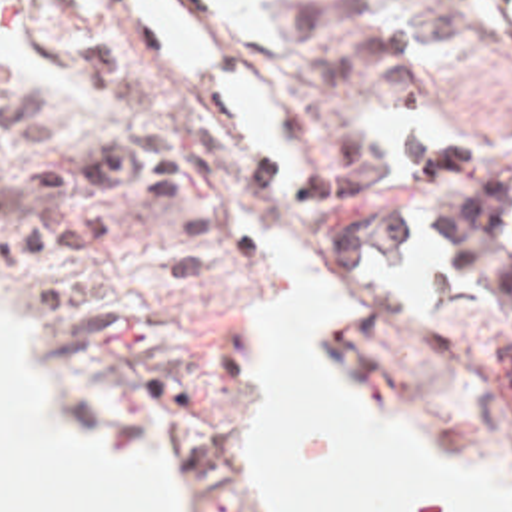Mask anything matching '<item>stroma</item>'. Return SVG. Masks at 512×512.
<instances>
[{
    "instance_id": "stroma-1",
    "label": "stroma",
    "mask_w": 512,
    "mask_h": 512,
    "mask_svg": "<svg viewBox=\"0 0 512 512\" xmlns=\"http://www.w3.org/2000/svg\"><path fill=\"white\" fill-rule=\"evenodd\" d=\"M169 2L211 38L217 66L275 70L339 176V214L303 216L223 136L211 78L181 82L131 0H107L105 20L76 0H0V62L58 108L50 146L0 156L40 168L111 134L115 110L76 72V48L100 42L209 210L201 285L157 273L151 222L107 186L52 202L109 214L94 244L26 254L0 228V267L44 313L74 393L167 441L197 479V512H235L225 425L255 391L263 273L247 234L289 230L385 297L329 373L379 389L421 449L491 465L512 489V40L493 0H255L279 56L247 50L201 0Z\"/></svg>"
}]
</instances>
